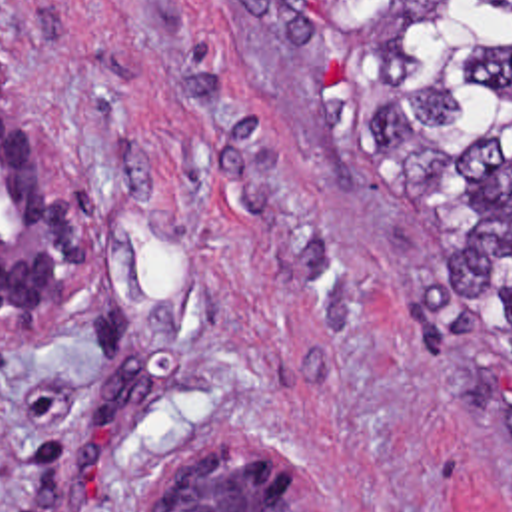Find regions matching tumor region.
Wrapping results in <instances>:
<instances>
[{
    "mask_svg": "<svg viewBox=\"0 0 512 512\" xmlns=\"http://www.w3.org/2000/svg\"><path fill=\"white\" fill-rule=\"evenodd\" d=\"M301 52L337 130L429 222L512 401V0H225Z\"/></svg>",
    "mask_w": 512,
    "mask_h": 512,
    "instance_id": "e687c5a6",
    "label": "tumor region"
}]
</instances>
